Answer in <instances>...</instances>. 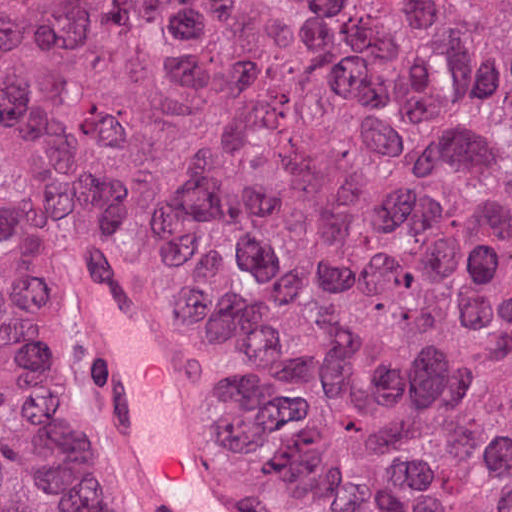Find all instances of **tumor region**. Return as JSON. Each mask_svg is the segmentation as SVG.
Here are the masks:
<instances>
[{"label": "tumor region", "instance_id": "e687c5a6", "mask_svg": "<svg viewBox=\"0 0 512 512\" xmlns=\"http://www.w3.org/2000/svg\"><path fill=\"white\" fill-rule=\"evenodd\" d=\"M91 232L277 512H512V0H0V512H136Z\"/></svg>", "mask_w": 512, "mask_h": 512}]
</instances>
